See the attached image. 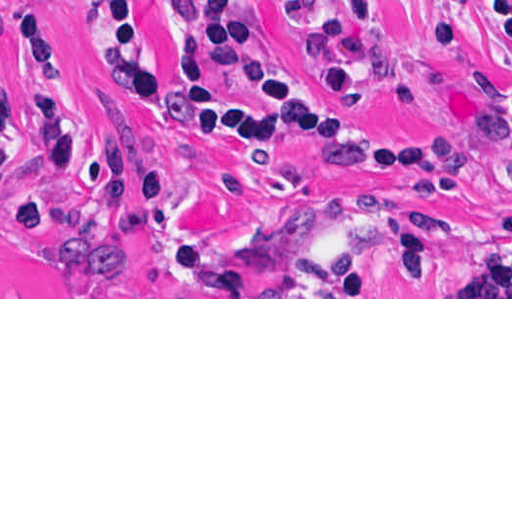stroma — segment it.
<instances>
[{
  "label": "stroma",
  "instance_id": "1",
  "mask_svg": "<svg viewBox=\"0 0 512 512\" xmlns=\"http://www.w3.org/2000/svg\"><path fill=\"white\" fill-rule=\"evenodd\" d=\"M157 65L184 77L193 64L180 0H139ZM50 16L64 94L81 124L70 167L52 174L33 161L55 145L61 122L24 96L17 76L20 0H0V299H512V273L481 271L452 288L471 257L512 216V144L489 128L512 108V41L479 19L447 58L452 83L407 110L367 82L353 96L364 126L432 160L438 176L392 175L317 144H274L258 153L208 147L165 125L113 76L83 5L41 0ZM327 20H354L356 0H315ZM264 43L323 94L330 82L294 34L279 0H245ZM390 52L387 79L421 65L439 25V0H380ZM153 148L170 195L139 221L113 255L114 268L81 279L93 216V165L104 141ZM41 216L17 231L14 170ZM370 199L412 216L437 245L429 290H387L397 277L386 239L369 245L358 279L335 290L348 232ZM225 257L255 293H166L151 268L180 242Z\"/></svg>",
  "mask_w": 512,
  "mask_h": 512
}]
</instances>
